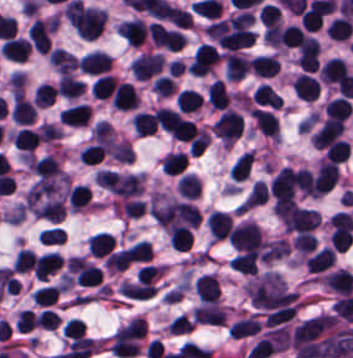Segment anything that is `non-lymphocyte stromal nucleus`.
Masks as SVG:
<instances>
[{
	"instance_id": "dd21d789",
	"label": "non-lymphocyte stromal nucleus",
	"mask_w": 353,
	"mask_h": 358,
	"mask_svg": "<svg viewBox=\"0 0 353 358\" xmlns=\"http://www.w3.org/2000/svg\"><path fill=\"white\" fill-rule=\"evenodd\" d=\"M69 178L38 181L27 193L23 206L37 216L63 220Z\"/></svg>"
}]
</instances>
